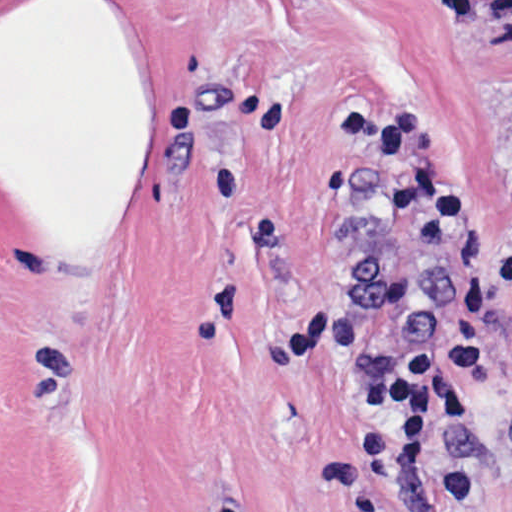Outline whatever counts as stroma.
Returning a JSON list of instances; mask_svg holds the SVG:
<instances>
[{"label": "stroma", "mask_w": 512, "mask_h": 512, "mask_svg": "<svg viewBox=\"0 0 512 512\" xmlns=\"http://www.w3.org/2000/svg\"><path fill=\"white\" fill-rule=\"evenodd\" d=\"M512 0H0V512H432L371 365L444 270L329 115L511 223ZM450 462L512 512V302Z\"/></svg>", "instance_id": "35a3bbf8"}]
</instances>
